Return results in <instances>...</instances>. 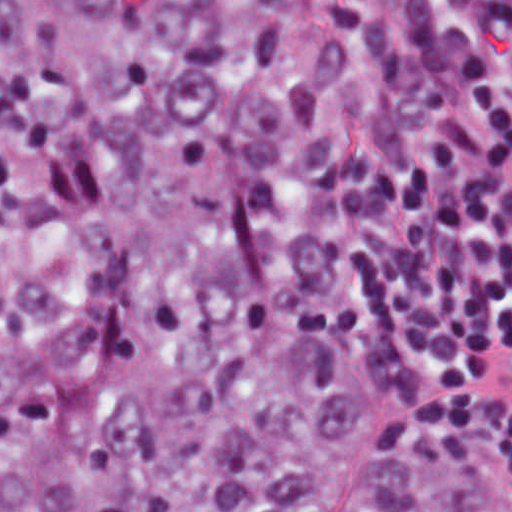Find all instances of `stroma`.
<instances>
[{
	"instance_id": "1",
	"label": "stroma",
	"mask_w": 512,
	"mask_h": 512,
	"mask_svg": "<svg viewBox=\"0 0 512 512\" xmlns=\"http://www.w3.org/2000/svg\"><path fill=\"white\" fill-rule=\"evenodd\" d=\"M495 57L503 73L504 91L508 99L512 101V35L497 46ZM324 267L329 282L335 288L347 294L340 282L336 259V131L333 139L330 166L324 193ZM366 324L378 348L404 366L422 389L436 401L428 380L410 367L400 344L374 332L367 322ZM493 466L502 485L512 497V486L494 464Z\"/></svg>"
}]
</instances>
